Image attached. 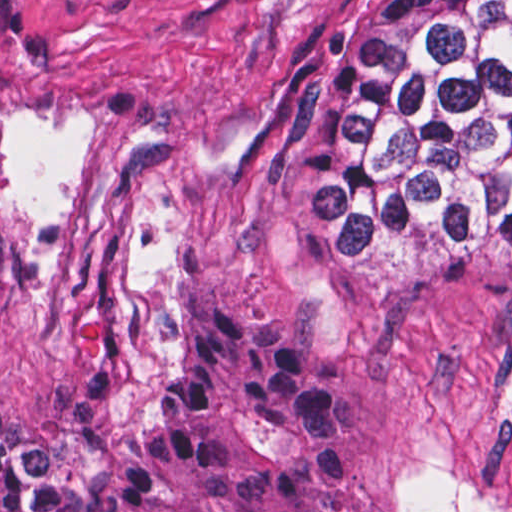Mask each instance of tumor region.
Segmentation results:
<instances>
[{"label":"tumor region","instance_id":"e687c5a6","mask_svg":"<svg viewBox=\"0 0 512 512\" xmlns=\"http://www.w3.org/2000/svg\"><path fill=\"white\" fill-rule=\"evenodd\" d=\"M309 250L417 222L444 267L512 228V0H366L305 129ZM80 430L0 416V512H354L358 383L197 297Z\"/></svg>","mask_w":512,"mask_h":512}]
</instances>
